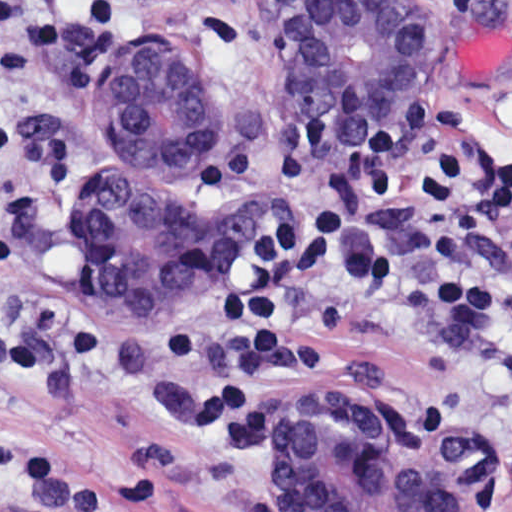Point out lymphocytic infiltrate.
<instances>
[{
	"mask_svg": "<svg viewBox=\"0 0 512 512\" xmlns=\"http://www.w3.org/2000/svg\"><path fill=\"white\" fill-rule=\"evenodd\" d=\"M462 105L446 96L406 98L367 132L330 136L296 110L280 114L263 142L213 150L203 164L211 194L256 179L280 193L266 252L225 269L219 310L164 348V371L199 396V419L226 451L275 443L281 394L352 350L335 340L442 342L472 355L512 343V290L431 293L401 287L379 301L337 303L343 266L382 267L391 243L352 223L330 188L350 179L368 202L407 193L427 222L417 271L436 284L468 273L470 244L496 278L512 280V165L492 148L470 162L456 135ZM0 130V272L20 267L70 193V171L50 149ZM86 351V327L64 303L40 305L0 329V393L44 395L65 386ZM0 487L27 504L19 512H150L156 496L134 468L91 476L66 452L0 438Z\"/></svg>",
	"mask_w": 512,
	"mask_h": 512,
	"instance_id": "lymphocytic-infiltrate-1",
	"label": "lymphocytic infiltrate"
}]
</instances>
